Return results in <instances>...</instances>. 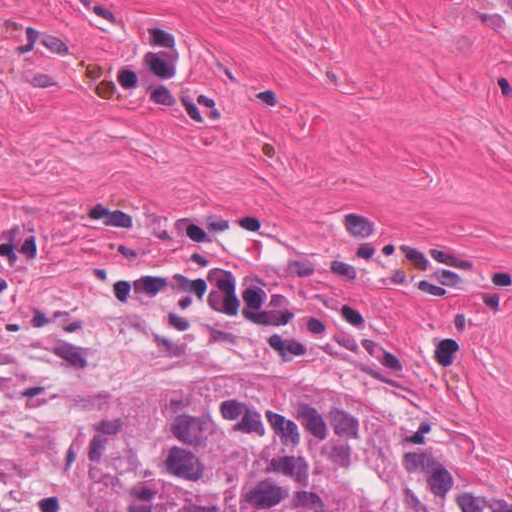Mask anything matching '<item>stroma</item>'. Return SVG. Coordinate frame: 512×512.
<instances>
[{
	"label": "stroma",
	"mask_w": 512,
	"mask_h": 512,
	"mask_svg": "<svg viewBox=\"0 0 512 512\" xmlns=\"http://www.w3.org/2000/svg\"><path fill=\"white\" fill-rule=\"evenodd\" d=\"M159 384H295L512 506V25L0 321V500L74 512Z\"/></svg>",
	"instance_id": "obj_1"
}]
</instances>
